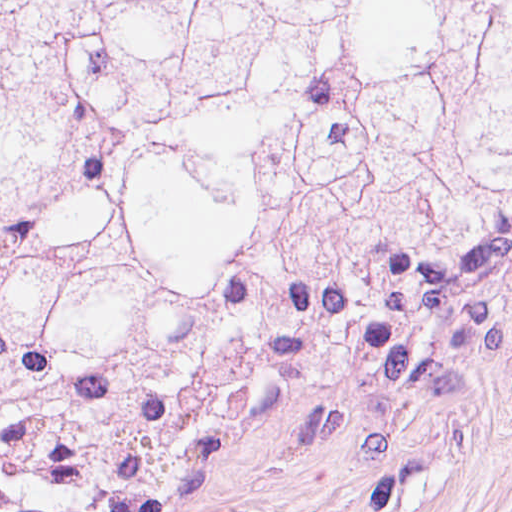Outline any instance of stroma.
Here are the masks:
<instances>
[{"instance_id":"stroma-1","label":"stroma","mask_w":512,"mask_h":512,"mask_svg":"<svg viewBox=\"0 0 512 512\" xmlns=\"http://www.w3.org/2000/svg\"><path fill=\"white\" fill-rule=\"evenodd\" d=\"M0 512H512V210L332 276L274 352Z\"/></svg>"}]
</instances>
